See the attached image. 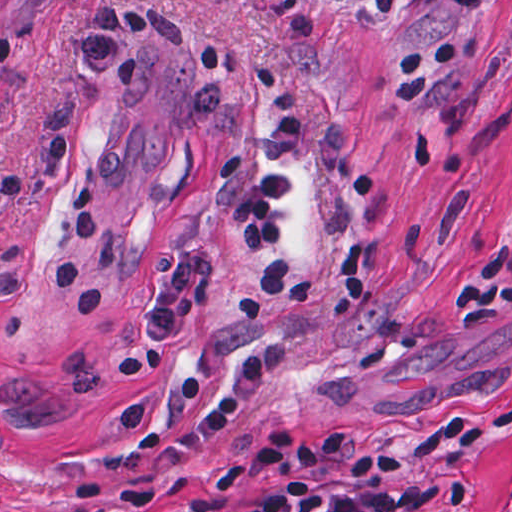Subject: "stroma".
<instances>
[{
	"instance_id": "obj_1",
	"label": "stroma",
	"mask_w": 512,
	"mask_h": 512,
	"mask_svg": "<svg viewBox=\"0 0 512 512\" xmlns=\"http://www.w3.org/2000/svg\"><path fill=\"white\" fill-rule=\"evenodd\" d=\"M260 60L309 104L287 259L345 292L361 245L349 314L225 304L263 265L227 217L273 123ZM365 431L454 470L422 512H512V0H0V512H221L255 492L238 446Z\"/></svg>"
}]
</instances>
